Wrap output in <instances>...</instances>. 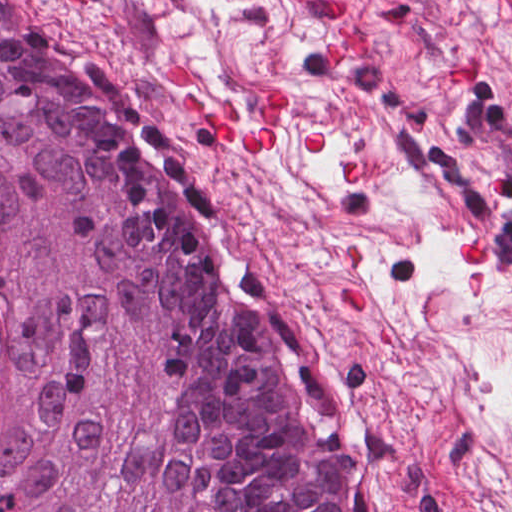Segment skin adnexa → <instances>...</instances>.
Masks as SVG:
<instances>
[{
  "mask_svg": "<svg viewBox=\"0 0 512 512\" xmlns=\"http://www.w3.org/2000/svg\"><path fill=\"white\" fill-rule=\"evenodd\" d=\"M174 128L0 0V512H372Z\"/></svg>",
  "mask_w": 512,
  "mask_h": 512,
  "instance_id": "obj_1",
  "label": "skin adnexa"
}]
</instances>
